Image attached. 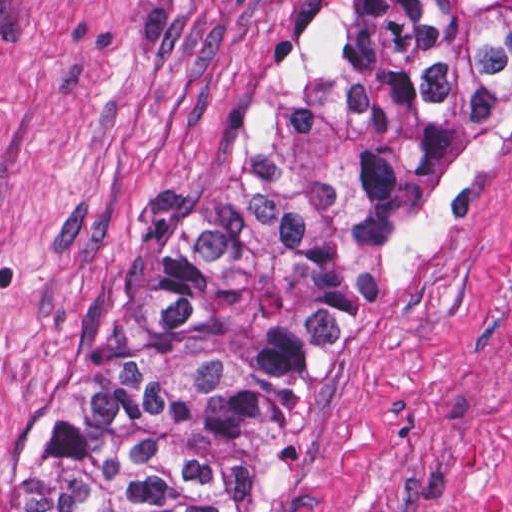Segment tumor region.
<instances>
[{"label":"tumor region","instance_id":"obj_1","mask_svg":"<svg viewBox=\"0 0 512 512\" xmlns=\"http://www.w3.org/2000/svg\"><path fill=\"white\" fill-rule=\"evenodd\" d=\"M512 117V1H348L0 469V512H277L363 318Z\"/></svg>","mask_w":512,"mask_h":512}]
</instances>
